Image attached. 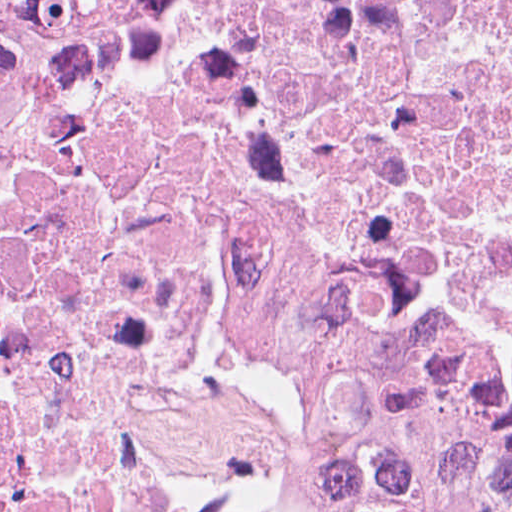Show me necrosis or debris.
Here are the masks:
<instances>
[{"mask_svg":"<svg viewBox=\"0 0 512 512\" xmlns=\"http://www.w3.org/2000/svg\"><path fill=\"white\" fill-rule=\"evenodd\" d=\"M0 512H512V0H165L2 127Z\"/></svg>","mask_w":512,"mask_h":512,"instance_id":"obj_1","label":"necrosis or debris"}]
</instances>
